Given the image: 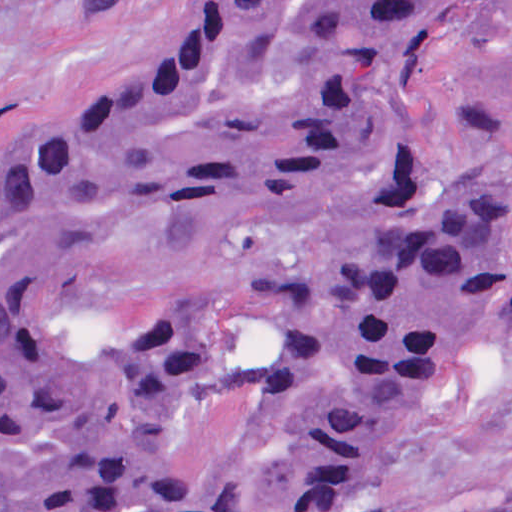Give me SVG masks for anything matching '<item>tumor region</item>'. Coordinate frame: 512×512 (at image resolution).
Masks as SVG:
<instances>
[{
	"mask_svg": "<svg viewBox=\"0 0 512 512\" xmlns=\"http://www.w3.org/2000/svg\"><path fill=\"white\" fill-rule=\"evenodd\" d=\"M483 0H207L0 154V512H336L512 346V171L420 170Z\"/></svg>",
	"mask_w": 512,
	"mask_h": 512,
	"instance_id": "obj_1",
	"label": "tumor region"
}]
</instances>
